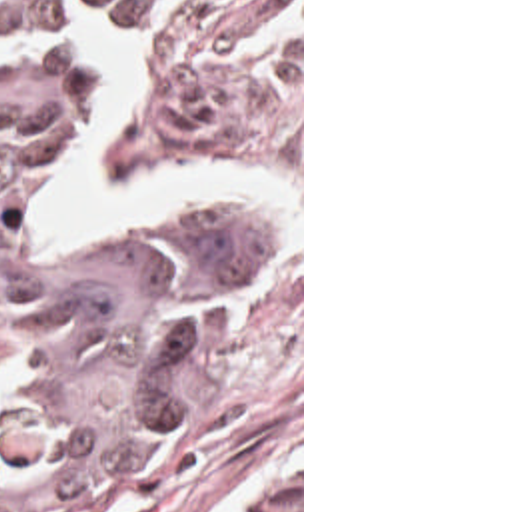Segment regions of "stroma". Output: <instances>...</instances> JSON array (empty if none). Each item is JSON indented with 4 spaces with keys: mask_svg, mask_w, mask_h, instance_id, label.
I'll use <instances>...</instances> for the list:
<instances>
[{
    "mask_svg": "<svg viewBox=\"0 0 512 512\" xmlns=\"http://www.w3.org/2000/svg\"><path fill=\"white\" fill-rule=\"evenodd\" d=\"M106 28L140 40L136 102L104 132L108 182L128 188L148 166H272L300 198V224L268 200L206 202L264 208L280 238L230 272L182 418L70 512H252L296 485L304 512V0H116L102 24L56 38L78 42L64 152L14 224L18 246L40 258L122 248L192 208L108 242H44L34 232L114 88L110 64L90 54ZM20 44L28 40H0V50ZM30 348L20 318L0 304V384L28 368Z\"/></svg>",
    "mask_w": 512,
    "mask_h": 512,
    "instance_id": "stroma-1",
    "label": "stroma"
}]
</instances>
